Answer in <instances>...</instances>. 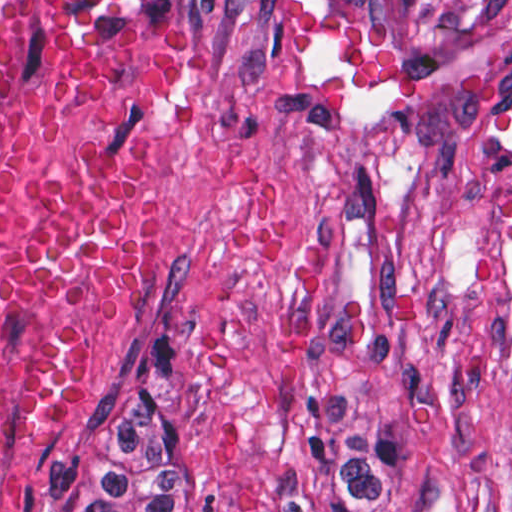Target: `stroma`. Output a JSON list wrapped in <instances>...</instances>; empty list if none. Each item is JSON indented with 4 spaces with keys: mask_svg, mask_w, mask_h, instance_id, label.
I'll return each instance as SVG.
<instances>
[{
    "mask_svg": "<svg viewBox=\"0 0 512 512\" xmlns=\"http://www.w3.org/2000/svg\"><path fill=\"white\" fill-rule=\"evenodd\" d=\"M214 512H512V0H225L123 372Z\"/></svg>",
    "mask_w": 512,
    "mask_h": 512,
    "instance_id": "35a3bbf8",
    "label": "stroma"
}]
</instances>
